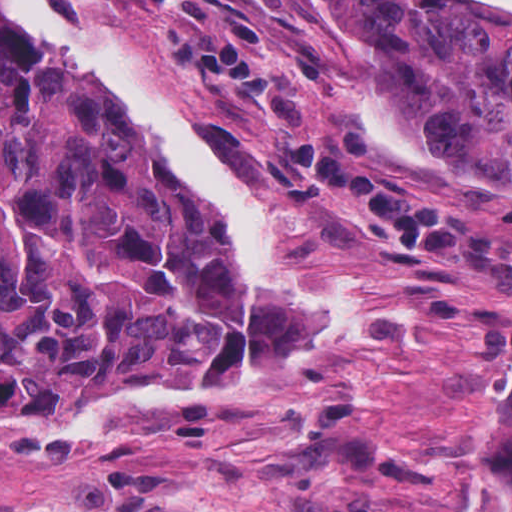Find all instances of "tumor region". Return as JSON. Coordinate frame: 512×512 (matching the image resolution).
Returning a JSON list of instances; mask_svg holds the SVG:
<instances>
[{"mask_svg":"<svg viewBox=\"0 0 512 512\" xmlns=\"http://www.w3.org/2000/svg\"><path fill=\"white\" fill-rule=\"evenodd\" d=\"M122 1L282 175L512 292V241L300 111L323 40L279 39L237 0ZM311 3L340 42L365 43L403 133L512 199V22L478 0ZM244 336L237 269L111 92L0 33V444L58 445L103 407L216 401ZM467 441L457 512H512V374L472 403Z\"/></svg>","mask_w":512,"mask_h":512,"instance_id":"e687c5a6","label":"tumor region"}]
</instances>
